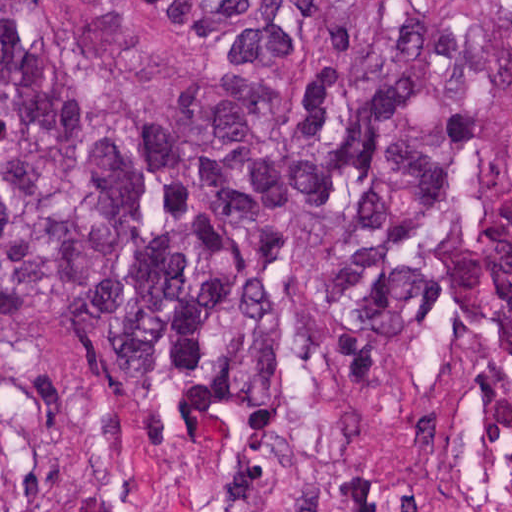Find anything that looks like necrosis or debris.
<instances>
[{"label":"necrosis or debris","mask_w":512,"mask_h":512,"mask_svg":"<svg viewBox=\"0 0 512 512\" xmlns=\"http://www.w3.org/2000/svg\"><path fill=\"white\" fill-rule=\"evenodd\" d=\"M256 512H512V481H465L379 507L328 474H299L270 483Z\"/></svg>","instance_id":"4bbe7bcc"}]
</instances>
